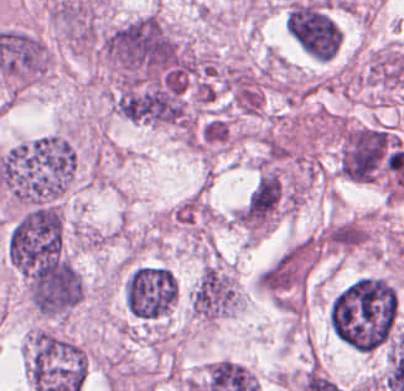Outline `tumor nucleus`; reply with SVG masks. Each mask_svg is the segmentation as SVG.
<instances>
[{
    "label": "tumor nucleus",
    "mask_w": 404,
    "mask_h": 391,
    "mask_svg": "<svg viewBox=\"0 0 404 391\" xmlns=\"http://www.w3.org/2000/svg\"><path fill=\"white\" fill-rule=\"evenodd\" d=\"M76 168L70 128L16 140L0 149V190L5 206L58 203L68 194Z\"/></svg>",
    "instance_id": "1"
},
{
    "label": "tumor nucleus",
    "mask_w": 404,
    "mask_h": 391,
    "mask_svg": "<svg viewBox=\"0 0 404 391\" xmlns=\"http://www.w3.org/2000/svg\"><path fill=\"white\" fill-rule=\"evenodd\" d=\"M398 318L394 285L385 277L360 276L335 292L326 320L332 335L353 351L383 347Z\"/></svg>",
    "instance_id": "2"
},
{
    "label": "tumor nucleus",
    "mask_w": 404,
    "mask_h": 391,
    "mask_svg": "<svg viewBox=\"0 0 404 391\" xmlns=\"http://www.w3.org/2000/svg\"><path fill=\"white\" fill-rule=\"evenodd\" d=\"M12 270L35 316L62 321L82 299V278L67 254L20 248Z\"/></svg>",
    "instance_id": "3"
},
{
    "label": "tumor nucleus",
    "mask_w": 404,
    "mask_h": 391,
    "mask_svg": "<svg viewBox=\"0 0 404 391\" xmlns=\"http://www.w3.org/2000/svg\"><path fill=\"white\" fill-rule=\"evenodd\" d=\"M120 295L130 317L160 319L171 311L176 301V279L163 264L133 263L122 277Z\"/></svg>",
    "instance_id": "4"
},
{
    "label": "tumor nucleus",
    "mask_w": 404,
    "mask_h": 391,
    "mask_svg": "<svg viewBox=\"0 0 404 391\" xmlns=\"http://www.w3.org/2000/svg\"><path fill=\"white\" fill-rule=\"evenodd\" d=\"M283 26L309 58L326 61L340 47L338 27L320 2L305 0L289 4L284 10Z\"/></svg>",
    "instance_id": "5"
}]
</instances>
